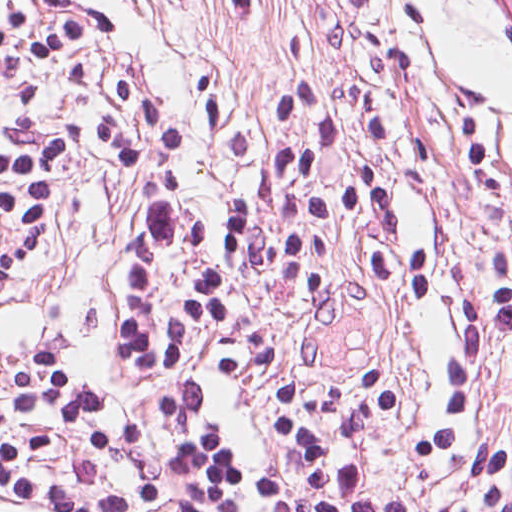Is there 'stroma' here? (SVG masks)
Segmentation results:
<instances>
[{"label": "stroma", "mask_w": 512, "mask_h": 512, "mask_svg": "<svg viewBox=\"0 0 512 512\" xmlns=\"http://www.w3.org/2000/svg\"><path fill=\"white\" fill-rule=\"evenodd\" d=\"M176 115L187 190L220 224L255 190L269 154L268 71L330 73L385 109L428 195L423 258L396 284L342 300L296 331L262 379L222 399L238 448L260 472L273 452L272 391L351 374L394 377L405 401L372 451L367 482L408 478L440 379L466 380L471 410L512 434V341L468 350L463 292L512 287V46L473 0H82ZM219 55L241 73L212 141L195 71ZM132 177L87 155L64 185L63 246L0 276V370L20 352L62 360L112 388ZM0 512H35L0 501ZM157 512V511H154Z\"/></svg>", "instance_id": "35a3bbf8"}]
</instances>
